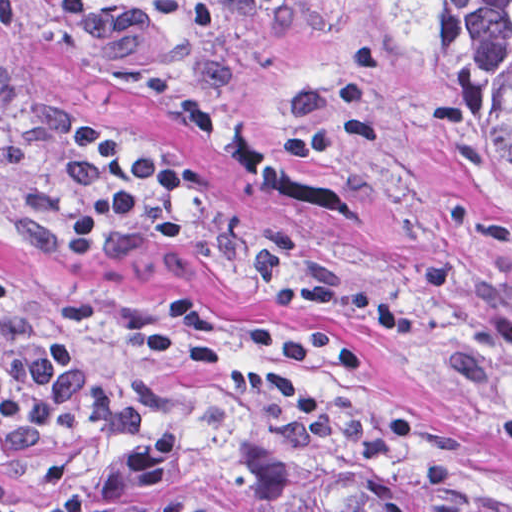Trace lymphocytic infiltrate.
<instances>
[{
  "instance_id": "1",
  "label": "lymphocytic infiltrate",
  "mask_w": 512,
  "mask_h": 512,
  "mask_svg": "<svg viewBox=\"0 0 512 512\" xmlns=\"http://www.w3.org/2000/svg\"><path fill=\"white\" fill-rule=\"evenodd\" d=\"M288 1V0H279ZM117 0H61L67 28L105 22ZM78 163L90 173L85 194L59 227L62 259L99 247L111 229L151 207L138 228L166 247L186 236L187 205L204 191L202 168L126 149L109 124L94 117L70 122ZM94 300H69L48 320L27 318L14 290L0 278V327L8 338L0 368V478L19 475L28 456L64 433L109 443H133L166 397V377L203 379L235 402L288 424L318 423L335 409L331 372L371 366L356 341H316L290 325H263L251 338L257 362L229 359L216 344L202 298L185 291L144 326L137 367L96 376L82 364V337L102 314ZM83 486L27 503L0 499V512H80Z\"/></svg>"
}]
</instances>
